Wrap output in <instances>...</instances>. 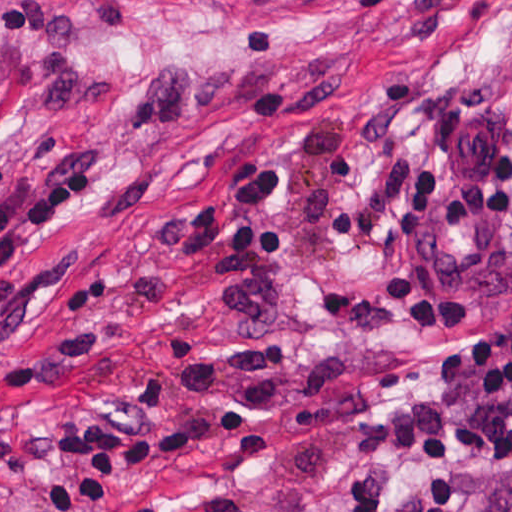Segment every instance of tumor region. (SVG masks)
Here are the masks:
<instances>
[{"label": "tumor region", "mask_w": 512, "mask_h": 512, "mask_svg": "<svg viewBox=\"0 0 512 512\" xmlns=\"http://www.w3.org/2000/svg\"><path fill=\"white\" fill-rule=\"evenodd\" d=\"M13 71V49L7 40L0 39V84ZM478 512H512V483L491 492Z\"/></svg>", "instance_id": "e687c5a6"}]
</instances>
